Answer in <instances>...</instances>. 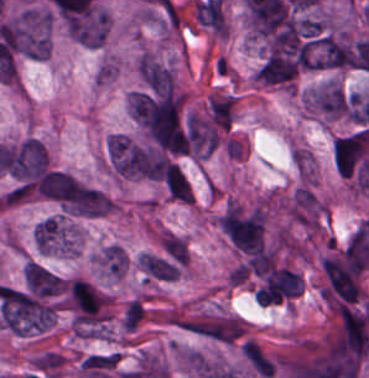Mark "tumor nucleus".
<instances>
[{
    "label": "tumor nucleus",
    "instance_id": "2",
    "mask_svg": "<svg viewBox=\"0 0 369 378\" xmlns=\"http://www.w3.org/2000/svg\"><path fill=\"white\" fill-rule=\"evenodd\" d=\"M241 353L254 374L264 378L273 377L275 363L254 339L248 338L241 345Z\"/></svg>",
    "mask_w": 369,
    "mask_h": 378
},
{
    "label": "tumor nucleus",
    "instance_id": "1",
    "mask_svg": "<svg viewBox=\"0 0 369 378\" xmlns=\"http://www.w3.org/2000/svg\"><path fill=\"white\" fill-rule=\"evenodd\" d=\"M350 94L335 81L309 91L307 110L329 119H347Z\"/></svg>",
    "mask_w": 369,
    "mask_h": 378
},
{
    "label": "tumor nucleus",
    "instance_id": "4",
    "mask_svg": "<svg viewBox=\"0 0 369 378\" xmlns=\"http://www.w3.org/2000/svg\"><path fill=\"white\" fill-rule=\"evenodd\" d=\"M160 247L166 257L174 262L187 265L188 254L184 239L165 233L161 235Z\"/></svg>",
    "mask_w": 369,
    "mask_h": 378
},
{
    "label": "tumor nucleus",
    "instance_id": "3",
    "mask_svg": "<svg viewBox=\"0 0 369 378\" xmlns=\"http://www.w3.org/2000/svg\"><path fill=\"white\" fill-rule=\"evenodd\" d=\"M207 107L212 121L228 129L233 113L232 96L210 94L207 100Z\"/></svg>",
    "mask_w": 369,
    "mask_h": 378
}]
</instances>
